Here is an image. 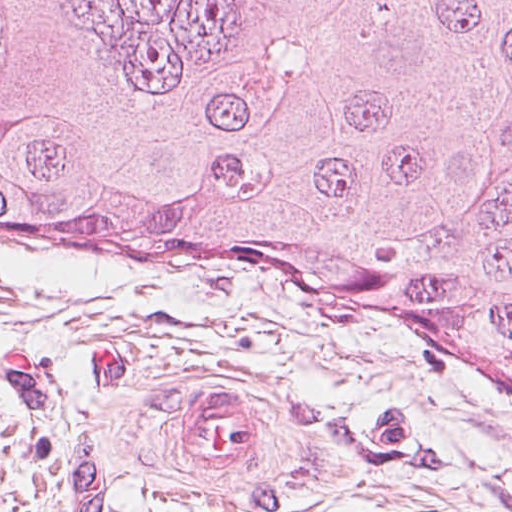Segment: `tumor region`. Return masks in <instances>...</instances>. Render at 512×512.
<instances>
[{
  "instance_id": "e687c5a6",
  "label": "tumor region",
  "mask_w": 512,
  "mask_h": 512,
  "mask_svg": "<svg viewBox=\"0 0 512 512\" xmlns=\"http://www.w3.org/2000/svg\"><path fill=\"white\" fill-rule=\"evenodd\" d=\"M0 249L345 282L512 389V0H0Z\"/></svg>"
}]
</instances>
